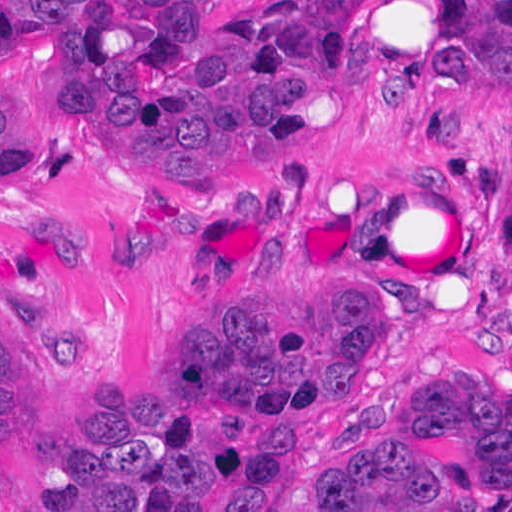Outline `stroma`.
Here are the masks:
<instances>
[{
  "label": "stroma",
  "mask_w": 512,
  "mask_h": 512,
  "mask_svg": "<svg viewBox=\"0 0 512 512\" xmlns=\"http://www.w3.org/2000/svg\"><path fill=\"white\" fill-rule=\"evenodd\" d=\"M276 1L193 0V14L199 31H229ZM338 76L267 164L213 193L153 198L82 121L48 46L0 34L1 102L49 162L0 189V285L54 402V433L34 459L0 464V512L62 499L95 450L105 386L182 361L204 298L391 301L375 389L334 411L245 512L290 510L335 441L435 376L512 402V83L455 63L447 0H368ZM393 84L413 95L400 112L381 99ZM66 219L93 229L83 271H62L33 243Z\"/></svg>",
  "instance_id": "1"
}]
</instances>
